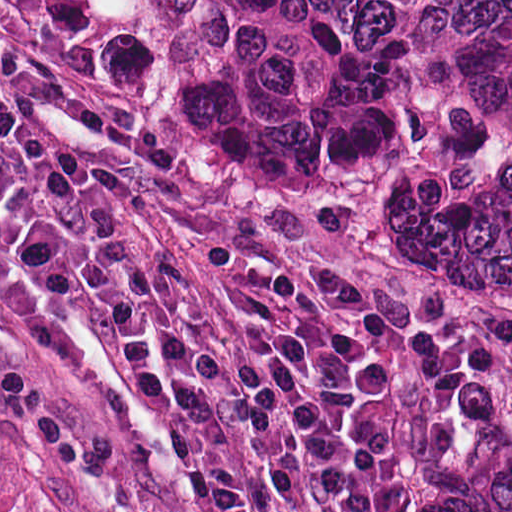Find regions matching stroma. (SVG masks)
<instances>
[{"mask_svg":"<svg viewBox=\"0 0 512 512\" xmlns=\"http://www.w3.org/2000/svg\"><path fill=\"white\" fill-rule=\"evenodd\" d=\"M0 90L130 169L140 186L115 215L215 293L195 246L238 243L310 283L320 264L344 270L365 295L364 319L382 309L449 349L436 386L384 403L396 446L380 512H405L457 401H512V244L24 85L0 79ZM215 423L259 512H311L263 485ZM0 469L30 512H198L102 349L36 294L12 240L0 248Z\"/></svg>","mask_w":512,"mask_h":512,"instance_id":"35a3bbf8","label":"stroma"}]
</instances>
